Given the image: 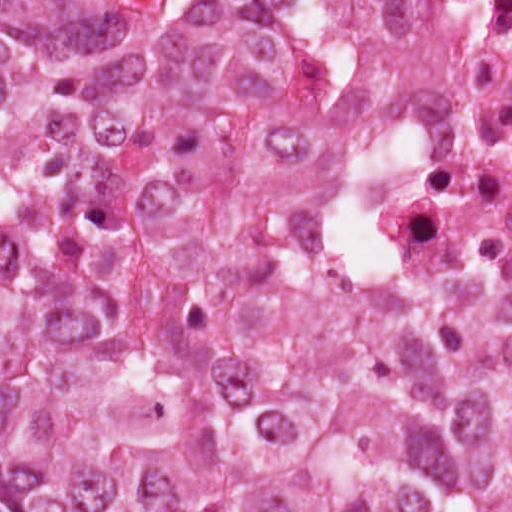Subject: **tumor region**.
<instances>
[{"instance_id":"obj_1","label":"tumor region","mask_w":512,"mask_h":512,"mask_svg":"<svg viewBox=\"0 0 512 512\" xmlns=\"http://www.w3.org/2000/svg\"><path fill=\"white\" fill-rule=\"evenodd\" d=\"M458 127L421 0H0V512H512Z\"/></svg>"}]
</instances>
